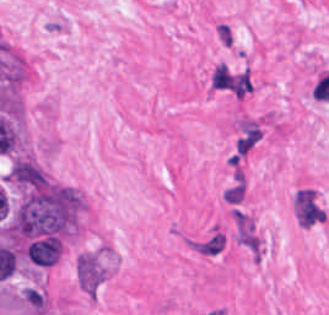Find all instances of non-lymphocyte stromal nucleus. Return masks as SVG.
I'll use <instances>...</instances> for the list:
<instances>
[{
	"mask_svg": "<svg viewBox=\"0 0 329 315\" xmlns=\"http://www.w3.org/2000/svg\"><path fill=\"white\" fill-rule=\"evenodd\" d=\"M226 234L218 227H211L192 236L184 242L195 253L205 257H215L221 253L225 244Z\"/></svg>",
	"mask_w": 329,
	"mask_h": 315,
	"instance_id": "1",
	"label": "non-lymphocyte stromal nucleus"
},
{
	"mask_svg": "<svg viewBox=\"0 0 329 315\" xmlns=\"http://www.w3.org/2000/svg\"><path fill=\"white\" fill-rule=\"evenodd\" d=\"M75 277L85 291H94L102 277V269L94 257L80 254L75 263Z\"/></svg>",
	"mask_w": 329,
	"mask_h": 315,
	"instance_id": "2",
	"label": "non-lymphocyte stromal nucleus"
}]
</instances>
